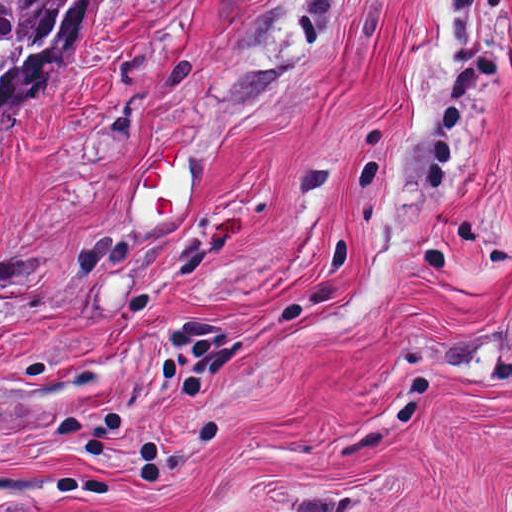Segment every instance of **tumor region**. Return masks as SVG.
Here are the masks:
<instances>
[{"instance_id":"e687c5a6","label":"tumor region","mask_w":512,"mask_h":512,"mask_svg":"<svg viewBox=\"0 0 512 512\" xmlns=\"http://www.w3.org/2000/svg\"><path fill=\"white\" fill-rule=\"evenodd\" d=\"M104 0H0V115L82 45Z\"/></svg>"}]
</instances>
